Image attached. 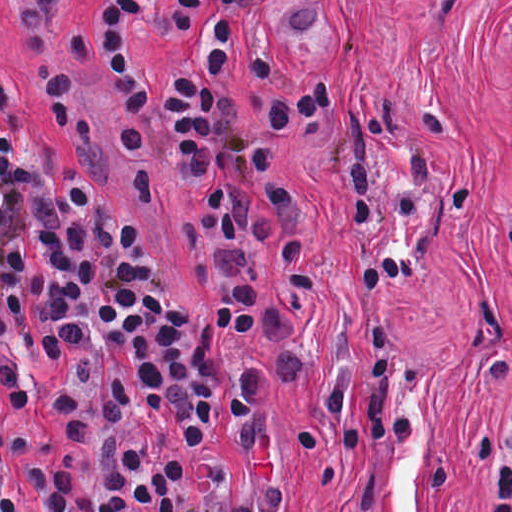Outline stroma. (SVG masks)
Masks as SVG:
<instances>
[{
    "mask_svg": "<svg viewBox=\"0 0 512 512\" xmlns=\"http://www.w3.org/2000/svg\"><path fill=\"white\" fill-rule=\"evenodd\" d=\"M301 0H258L246 43L275 76L227 86L253 108L330 78L337 102L278 140L277 150L325 222L316 291L295 287L273 242L262 267L293 320L303 368L260 408L289 477V512H483L475 434L483 415L512 397V0H326L303 32ZM57 42L90 116L81 166L100 194L131 213L181 297L234 350L237 326L220 295L209 218L219 183L195 167L163 193L145 194L111 77L101 0H50ZM19 0H0V73L55 160L51 106L26 58ZM427 93L457 110L447 142L415 137L437 166L456 173L467 206L435 223L417 272L388 292L351 286L345 270V206L329 170L367 131L376 185L386 189L402 138ZM399 358L409 412L406 449L391 466L377 448L355 449L325 425L332 380L346 374L348 419L361 425L386 343ZM0 427L17 476L18 512H43L41 462L68 452L57 404L24 408L0 374Z\"/></svg>",
    "mask_w": 512,
    "mask_h": 512,
    "instance_id": "1",
    "label": "stroma"
}]
</instances>
